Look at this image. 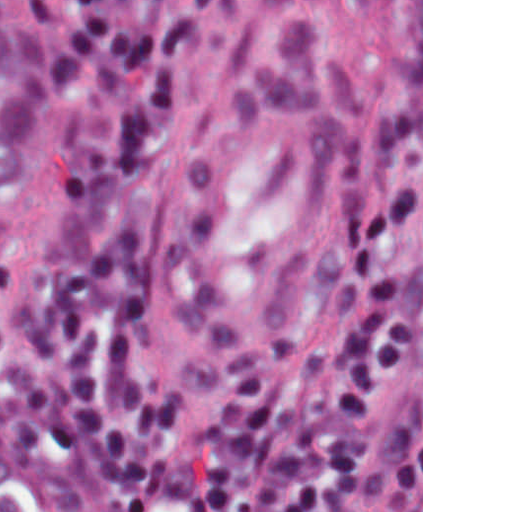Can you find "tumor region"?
I'll list each match as a JSON object with an SVG mask.
<instances>
[{"label":"tumor region","mask_w":512,"mask_h":512,"mask_svg":"<svg viewBox=\"0 0 512 512\" xmlns=\"http://www.w3.org/2000/svg\"><path fill=\"white\" fill-rule=\"evenodd\" d=\"M64 1H0V273L31 239L50 167L55 12Z\"/></svg>","instance_id":"e687c5a6"}]
</instances>
